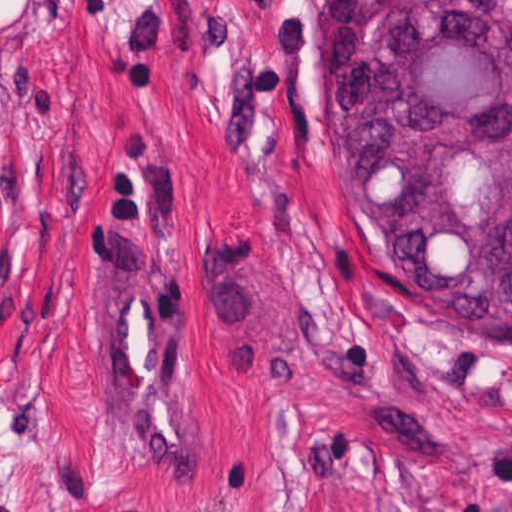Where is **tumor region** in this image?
<instances>
[{"label": "tumor region", "instance_id": "obj_1", "mask_svg": "<svg viewBox=\"0 0 512 512\" xmlns=\"http://www.w3.org/2000/svg\"><path fill=\"white\" fill-rule=\"evenodd\" d=\"M333 59L384 272L424 315L512 346V0H334ZM382 512L480 511L455 485H406Z\"/></svg>", "mask_w": 512, "mask_h": 512}]
</instances>
